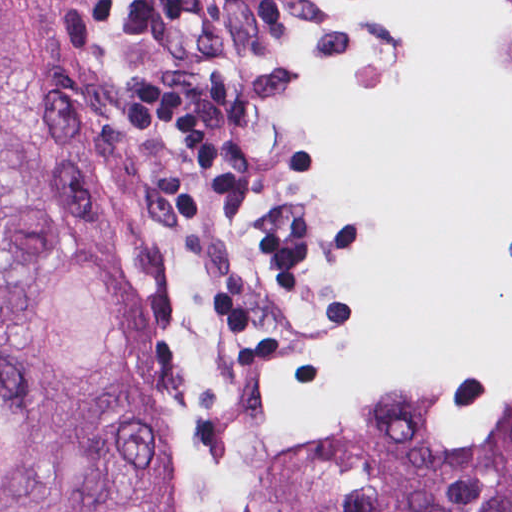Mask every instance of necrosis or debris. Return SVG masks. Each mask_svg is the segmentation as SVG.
<instances>
[{"instance_id": "obj_1", "label": "necrosis or debris", "mask_w": 512, "mask_h": 512, "mask_svg": "<svg viewBox=\"0 0 512 512\" xmlns=\"http://www.w3.org/2000/svg\"><path fill=\"white\" fill-rule=\"evenodd\" d=\"M290 58L89 99L101 284L193 512H297L366 342L375 194L512 246V0H287Z\"/></svg>"}]
</instances>
